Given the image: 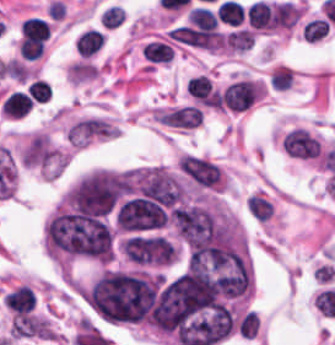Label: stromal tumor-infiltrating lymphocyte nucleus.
<instances>
[{"mask_svg": "<svg viewBox=\"0 0 335 345\" xmlns=\"http://www.w3.org/2000/svg\"><path fill=\"white\" fill-rule=\"evenodd\" d=\"M320 140L302 126H295L282 138L283 150L292 157H317Z\"/></svg>", "mask_w": 335, "mask_h": 345, "instance_id": "1", "label": "stromal tumor-infiltrating lymphocyte nucleus"}, {"mask_svg": "<svg viewBox=\"0 0 335 345\" xmlns=\"http://www.w3.org/2000/svg\"><path fill=\"white\" fill-rule=\"evenodd\" d=\"M249 24L257 29L271 31L274 29L269 2L254 1L245 11Z\"/></svg>", "mask_w": 335, "mask_h": 345, "instance_id": "2", "label": "stromal tumor-infiltrating lymphocyte nucleus"}, {"mask_svg": "<svg viewBox=\"0 0 335 345\" xmlns=\"http://www.w3.org/2000/svg\"><path fill=\"white\" fill-rule=\"evenodd\" d=\"M104 38L102 31L88 27L74 39V46L80 54L90 56L99 50Z\"/></svg>", "mask_w": 335, "mask_h": 345, "instance_id": "3", "label": "stromal tumor-infiltrating lymphocyte nucleus"}, {"mask_svg": "<svg viewBox=\"0 0 335 345\" xmlns=\"http://www.w3.org/2000/svg\"><path fill=\"white\" fill-rule=\"evenodd\" d=\"M30 101L29 93L14 90L5 97L1 109L7 116H22L29 111Z\"/></svg>", "mask_w": 335, "mask_h": 345, "instance_id": "4", "label": "stromal tumor-infiltrating lymphocyte nucleus"}, {"mask_svg": "<svg viewBox=\"0 0 335 345\" xmlns=\"http://www.w3.org/2000/svg\"><path fill=\"white\" fill-rule=\"evenodd\" d=\"M255 31L247 27H240L225 36V45L239 52L251 49L254 42Z\"/></svg>", "mask_w": 335, "mask_h": 345, "instance_id": "5", "label": "stromal tumor-infiltrating lymphocyte nucleus"}, {"mask_svg": "<svg viewBox=\"0 0 335 345\" xmlns=\"http://www.w3.org/2000/svg\"><path fill=\"white\" fill-rule=\"evenodd\" d=\"M144 57L153 62L168 63L172 59L171 45L162 40H149L141 48Z\"/></svg>", "mask_w": 335, "mask_h": 345, "instance_id": "6", "label": "stromal tumor-infiltrating lymphocyte nucleus"}, {"mask_svg": "<svg viewBox=\"0 0 335 345\" xmlns=\"http://www.w3.org/2000/svg\"><path fill=\"white\" fill-rule=\"evenodd\" d=\"M186 87L193 98L202 100H209L214 91L213 82L208 74H195L188 79Z\"/></svg>", "mask_w": 335, "mask_h": 345, "instance_id": "7", "label": "stromal tumor-infiltrating lymphocyte nucleus"}, {"mask_svg": "<svg viewBox=\"0 0 335 345\" xmlns=\"http://www.w3.org/2000/svg\"><path fill=\"white\" fill-rule=\"evenodd\" d=\"M215 12L222 22L239 26L245 15L240 1L237 0H224Z\"/></svg>", "mask_w": 335, "mask_h": 345, "instance_id": "8", "label": "stromal tumor-infiltrating lymphocyte nucleus"}, {"mask_svg": "<svg viewBox=\"0 0 335 345\" xmlns=\"http://www.w3.org/2000/svg\"><path fill=\"white\" fill-rule=\"evenodd\" d=\"M188 21L196 27L203 29L216 28L218 21L215 13L204 7L203 5H196L187 12Z\"/></svg>", "mask_w": 335, "mask_h": 345, "instance_id": "9", "label": "stromal tumor-infiltrating lymphocyte nucleus"}, {"mask_svg": "<svg viewBox=\"0 0 335 345\" xmlns=\"http://www.w3.org/2000/svg\"><path fill=\"white\" fill-rule=\"evenodd\" d=\"M247 210L257 220H267L273 212L272 205L258 194H251L246 203Z\"/></svg>", "mask_w": 335, "mask_h": 345, "instance_id": "10", "label": "stromal tumor-infiltrating lymphocyte nucleus"}, {"mask_svg": "<svg viewBox=\"0 0 335 345\" xmlns=\"http://www.w3.org/2000/svg\"><path fill=\"white\" fill-rule=\"evenodd\" d=\"M329 27L325 18L314 17L305 22L303 26L304 38L319 40L328 34Z\"/></svg>", "mask_w": 335, "mask_h": 345, "instance_id": "11", "label": "stromal tumor-infiltrating lymphocyte nucleus"}, {"mask_svg": "<svg viewBox=\"0 0 335 345\" xmlns=\"http://www.w3.org/2000/svg\"><path fill=\"white\" fill-rule=\"evenodd\" d=\"M26 92L36 102H46L51 97V85L35 78L26 87Z\"/></svg>", "mask_w": 335, "mask_h": 345, "instance_id": "12", "label": "stromal tumor-infiltrating lymphocyte nucleus"}, {"mask_svg": "<svg viewBox=\"0 0 335 345\" xmlns=\"http://www.w3.org/2000/svg\"><path fill=\"white\" fill-rule=\"evenodd\" d=\"M123 10L122 7L118 5H111L104 11H102L100 16V22L109 27H116L122 23Z\"/></svg>", "mask_w": 335, "mask_h": 345, "instance_id": "13", "label": "stromal tumor-infiltrating lymphocyte nucleus"}]
</instances>
